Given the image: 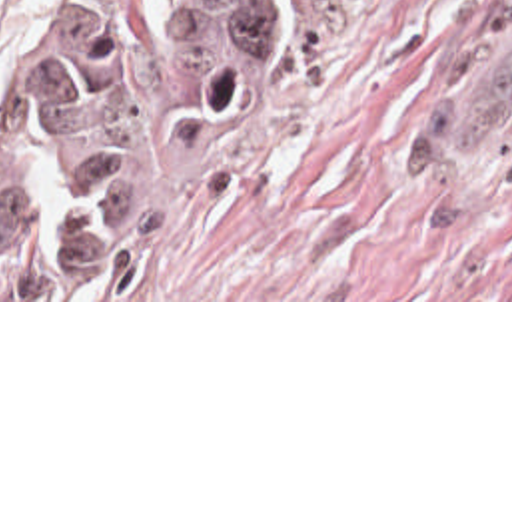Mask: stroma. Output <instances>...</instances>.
<instances>
[{
	"instance_id": "35a3bbf8",
	"label": "stroma",
	"mask_w": 512,
	"mask_h": 512,
	"mask_svg": "<svg viewBox=\"0 0 512 512\" xmlns=\"http://www.w3.org/2000/svg\"><path fill=\"white\" fill-rule=\"evenodd\" d=\"M0 0L5 68L31 19ZM161 150L155 232L105 278L0 302H512V0H273L231 96L169 68L163 0H117Z\"/></svg>"
}]
</instances>
